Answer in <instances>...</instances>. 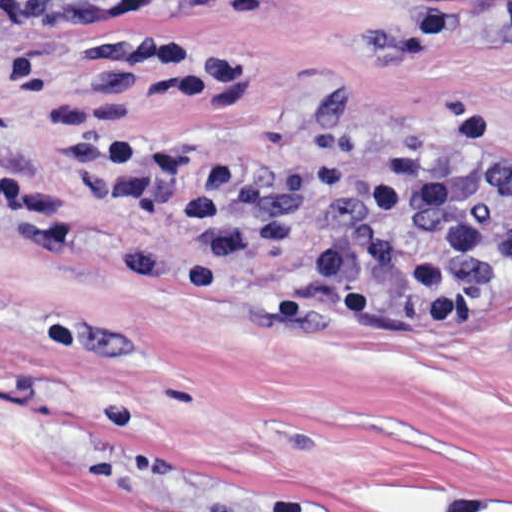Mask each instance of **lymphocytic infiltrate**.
<instances>
[{"label": "lymphocytic infiltrate", "instance_id": "f902f5d3", "mask_svg": "<svg viewBox=\"0 0 512 512\" xmlns=\"http://www.w3.org/2000/svg\"><path fill=\"white\" fill-rule=\"evenodd\" d=\"M85 69L63 91L54 128L82 191L156 213L179 248L129 247L119 264L173 297L240 296L280 266L264 308L280 327L400 330L479 324L512 277V157L489 107H445L418 131L374 133L363 94L308 104L302 158L214 149L137 127L143 99L205 101L237 90L240 57L189 39H80ZM0 231L36 248L69 235L48 199L0 169Z\"/></svg>", "mask_w": 512, "mask_h": 512}]
</instances>
